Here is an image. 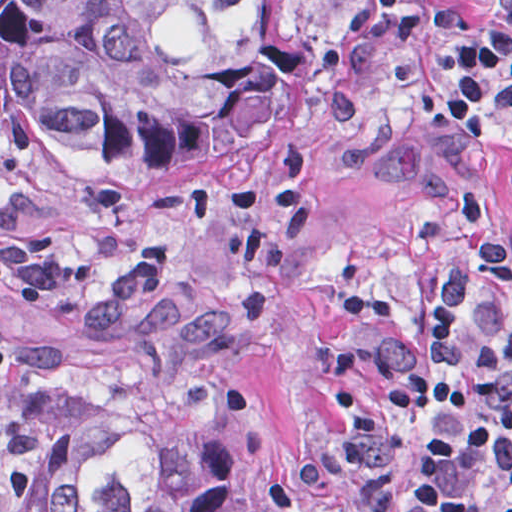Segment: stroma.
I'll list each match as a JSON object with an SVG mask.
<instances>
[{
    "mask_svg": "<svg viewBox=\"0 0 512 512\" xmlns=\"http://www.w3.org/2000/svg\"><path fill=\"white\" fill-rule=\"evenodd\" d=\"M478 23L372 51L384 85L359 130L338 128L316 67L341 2L261 0L265 36L306 41L284 116L235 158L196 173H77L0 161V189L45 199L0 249L81 239L85 207L140 212L144 237L84 284L14 315L0 353L1 417L18 338L79 309L133 261L155 300L211 284L232 304L231 377L266 425L251 512H287L324 408L380 331L471 245L512 231V118L474 144L452 113L453 59L502 21L505 0H468Z\"/></svg>",
    "mask_w": 512,
    "mask_h": 512,
    "instance_id": "1",
    "label": "stroma"
}]
</instances>
